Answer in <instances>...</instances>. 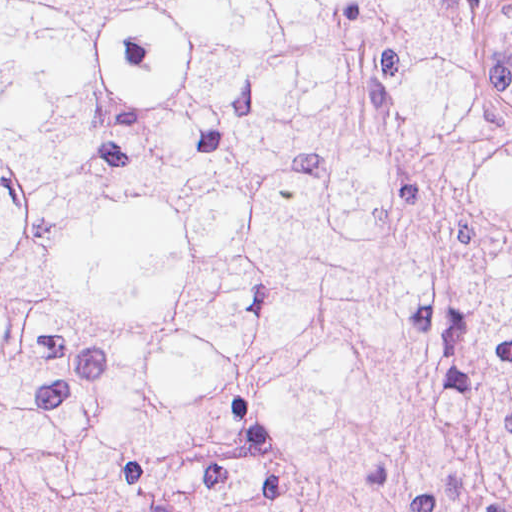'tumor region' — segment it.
Listing matches in <instances>:
<instances>
[{"label": "tumor region", "mask_w": 512, "mask_h": 512, "mask_svg": "<svg viewBox=\"0 0 512 512\" xmlns=\"http://www.w3.org/2000/svg\"><path fill=\"white\" fill-rule=\"evenodd\" d=\"M0 512H512V0H0Z\"/></svg>", "instance_id": "obj_1"}]
</instances>
